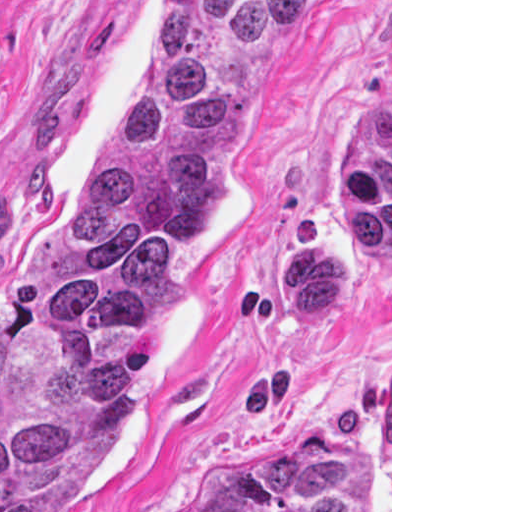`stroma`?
<instances>
[{"label": "stroma", "mask_w": 512, "mask_h": 512, "mask_svg": "<svg viewBox=\"0 0 512 512\" xmlns=\"http://www.w3.org/2000/svg\"><path fill=\"white\" fill-rule=\"evenodd\" d=\"M153 0H0V282L87 190ZM296 427L392 512V0H305L154 322L128 429L56 512H179Z\"/></svg>", "instance_id": "stroma-1"}]
</instances>
